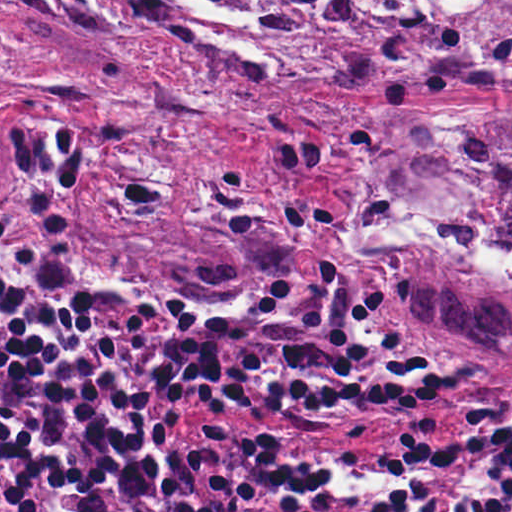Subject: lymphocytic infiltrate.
Returning <instances> with one entry per match:
<instances>
[{"mask_svg":"<svg viewBox=\"0 0 512 512\" xmlns=\"http://www.w3.org/2000/svg\"><path fill=\"white\" fill-rule=\"evenodd\" d=\"M269 423H418L454 454L436 512H512V379L421 348L329 264L192 317L96 293L77 316L0 232V512H420L441 474L412 435Z\"/></svg>","mask_w":512,"mask_h":512,"instance_id":"lymphocytic-infiltrate-1","label":"lymphocytic infiltrate"}]
</instances>
